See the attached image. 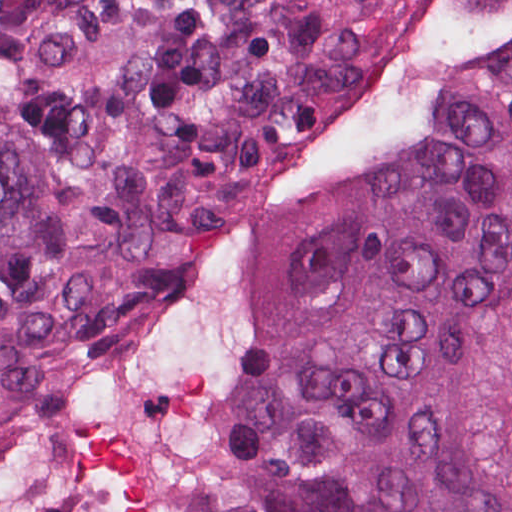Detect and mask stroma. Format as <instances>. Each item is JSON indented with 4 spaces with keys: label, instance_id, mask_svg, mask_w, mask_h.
I'll list each match as a JSON object with an SVG mask.
<instances>
[{
    "label": "stroma",
    "instance_id": "obj_1",
    "mask_svg": "<svg viewBox=\"0 0 512 512\" xmlns=\"http://www.w3.org/2000/svg\"><path fill=\"white\" fill-rule=\"evenodd\" d=\"M262 173L263 171L253 177L208 214L163 267L138 312L99 351L130 332L159 308L174 280L223 233ZM260 352L261 348L251 322L246 352V379L256 371ZM242 495L216 459L211 473V512H227Z\"/></svg>",
    "mask_w": 512,
    "mask_h": 512
}]
</instances>
